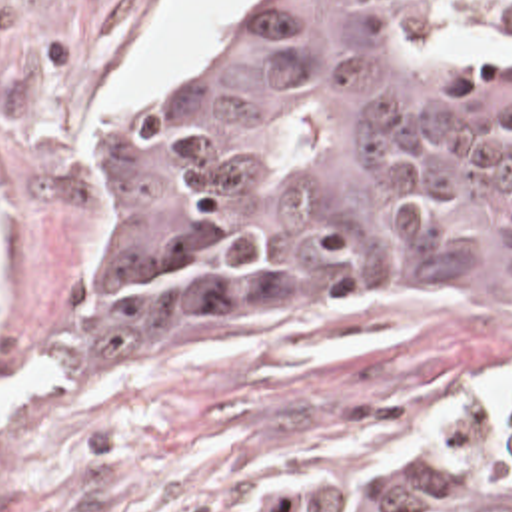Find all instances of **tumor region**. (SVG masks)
I'll list each match as a JSON object with an SVG mask.
<instances>
[{
	"mask_svg": "<svg viewBox=\"0 0 512 512\" xmlns=\"http://www.w3.org/2000/svg\"><path fill=\"white\" fill-rule=\"evenodd\" d=\"M445 34L512 40V0H269L239 52L97 138L119 222L65 352L135 378L181 308L275 284L512 302V52ZM243 512H512V386Z\"/></svg>",
	"mask_w": 512,
	"mask_h": 512,
	"instance_id": "e687c5a6",
	"label": "tumor region"
}]
</instances>
